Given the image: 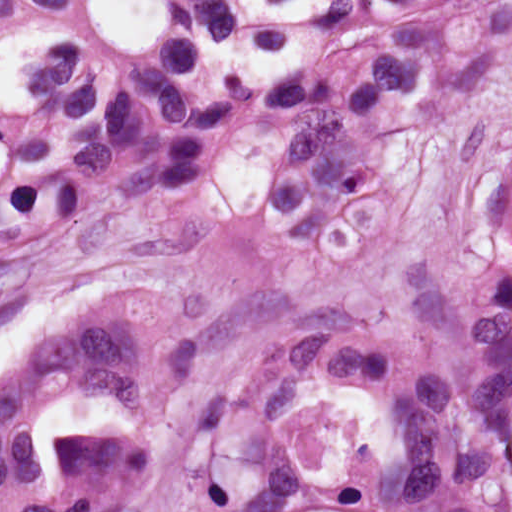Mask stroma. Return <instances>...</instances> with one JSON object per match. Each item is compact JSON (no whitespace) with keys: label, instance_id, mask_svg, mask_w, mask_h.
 Masks as SVG:
<instances>
[{"label":"stroma","instance_id":"stroma-1","mask_svg":"<svg viewBox=\"0 0 512 512\" xmlns=\"http://www.w3.org/2000/svg\"><path fill=\"white\" fill-rule=\"evenodd\" d=\"M293 136V123L264 115L223 133L198 185L122 200L111 183L0 232L45 336L132 293L181 295L199 315L202 364L158 420L112 395L75 400L89 434L146 450V487L127 512L313 340L402 351L405 261L462 253L481 193L512 159V69L450 98L431 79L405 96L391 127L402 207L356 263H304L275 244L260 191ZM498 512H512V466Z\"/></svg>","mask_w":512,"mask_h":512}]
</instances>
